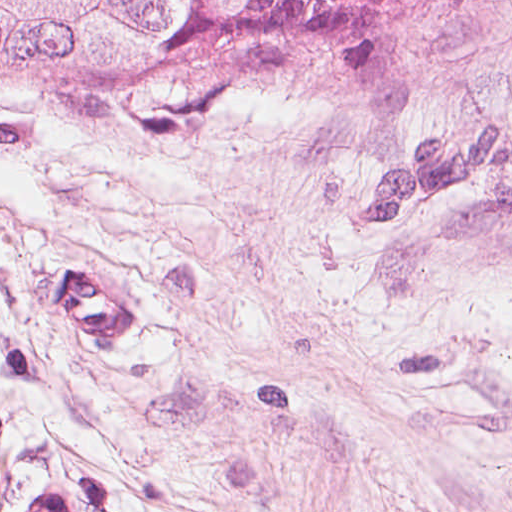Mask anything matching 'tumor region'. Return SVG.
I'll return each mask as SVG.
<instances>
[{"label": "tumor region", "instance_id": "1", "mask_svg": "<svg viewBox=\"0 0 512 512\" xmlns=\"http://www.w3.org/2000/svg\"><path fill=\"white\" fill-rule=\"evenodd\" d=\"M476 0H0V88L155 138L398 70Z\"/></svg>", "mask_w": 512, "mask_h": 512}]
</instances>
